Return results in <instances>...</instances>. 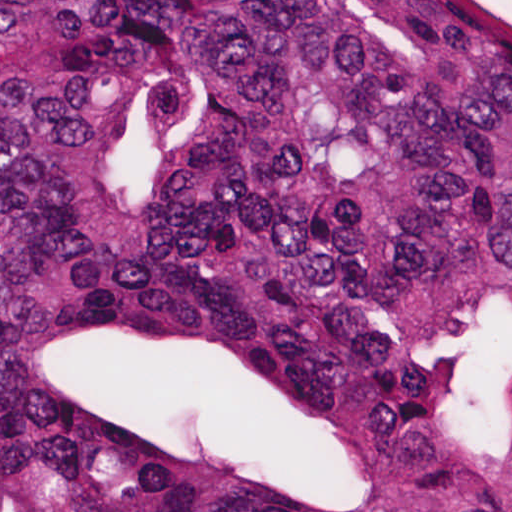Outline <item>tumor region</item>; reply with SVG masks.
I'll list each match as a JSON object with an SVG mask.
<instances>
[{"label":"tumor region","instance_id":"1","mask_svg":"<svg viewBox=\"0 0 512 512\" xmlns=\"http://www.w3.org/2000/svg\"><path fill=\"white\" fill-rule=\"evenodd\" d=\"M0 512H512V14L0 0Z\"/></svg>","mask_w":512,"mask_h":512}]
</instances>
